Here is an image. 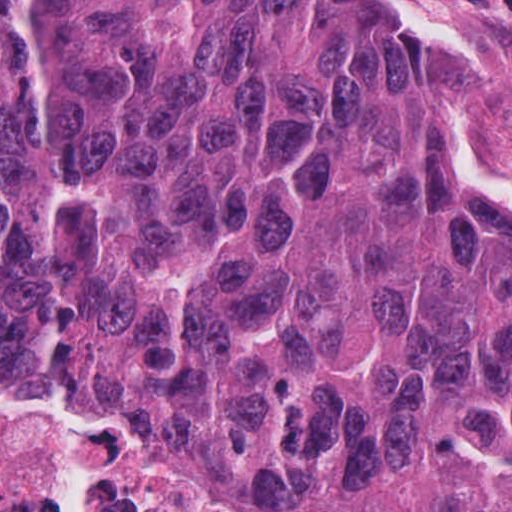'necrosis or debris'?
I'll list each match as a JSON object with an SVG mask.
<instances>
[{
    "instance_id": "1",
    "label": "necrosis or debris",
    "mask_w": 512,
    "mask_h": 512,
    "mask_svg": "<svg viewBox=\"0 0 512 512\" xmlns=\"http://www.w3.org/2000/svg\"><path fill=\"white\" fill-rule=\"evenodd\" d=\"M0 512H337L270 471L0 372Z\"/></svg>"
}]
</instances>
